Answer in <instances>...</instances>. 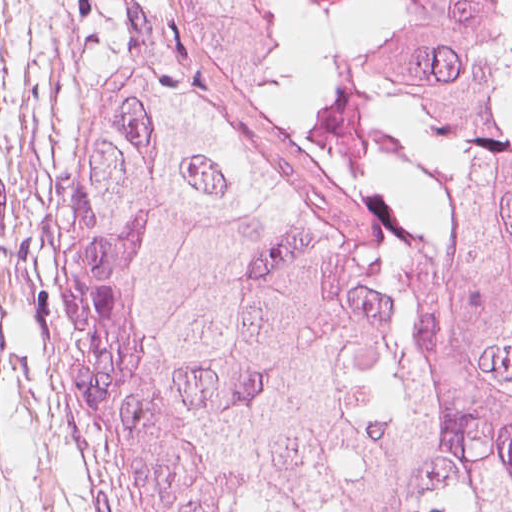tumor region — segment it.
<instances>
[{
    "mask_svg": "<svg viewBox=\"0 0 512 512\" xmlns=\"http://www.w3.org/2000/svg\"><path fill=\"white\" fill-rule=\"evenodd\" d=\"M55 393L96 512H512V115L384 130L282 0H109Z\"/></svg>",
    "mask_w": 512,
    "mask_h": 512,
    "instance_id": "e687c5a6",
    "label": "tumor region"
}]
</instances>
